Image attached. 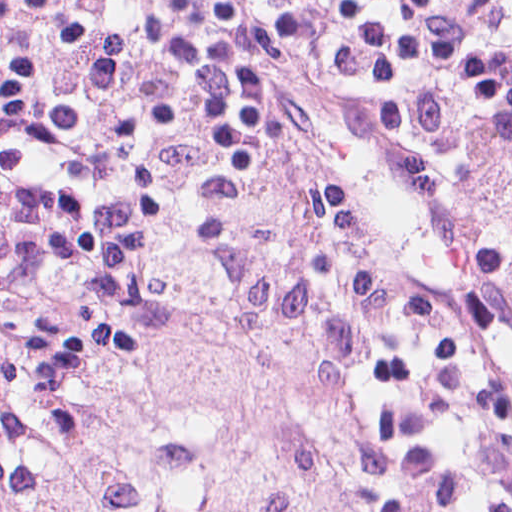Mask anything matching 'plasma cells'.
<instances>
[{"label": "plasma cells", "mask_w": 512, "mask_h": 512, "mask_svg": "<svg viewBox=\"0 0 512 512\" xmlns=\"http://www.w3.org/2000/svg\"><path fill=\"white\" fill-rule=\"evenodd\" d=\"M431 0H0V278L107 262L316 60L425 88Z\"/></svg>", "instance_id": "plasma-cells-1"}]
</instances>
